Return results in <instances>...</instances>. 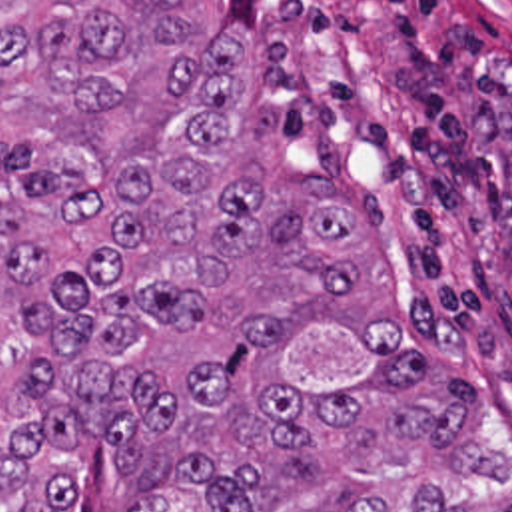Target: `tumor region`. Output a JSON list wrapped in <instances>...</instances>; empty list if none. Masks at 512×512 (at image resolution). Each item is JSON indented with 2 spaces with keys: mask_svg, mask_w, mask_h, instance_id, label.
<instances>
[{
  "mask_svg": "<svg viewBox=\"0 0 512 512\" xmlns=\"http://www.w3.org/2000/svg\"><path fill=\"white\" fill-rule=\"evenodd\" d=\"M189 0H0V512H512L476 393L349 320L359 224ZM512 194V114L498 126Z\"/></svg>",
  "mask_w": 512,
  "mask_h": 512,
  "instance_id": "1",
  "label": "tumor region"
}]
</instances>
